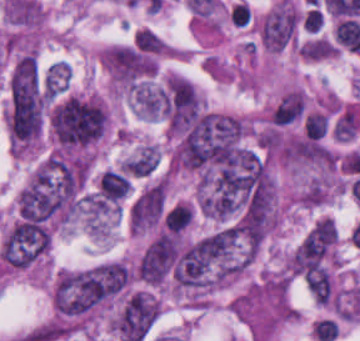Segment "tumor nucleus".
Instances as JSON below:
<instances>
[{"mask_svg": "<svg viewBox=\"0 0 360 341\" xmlns=\"http://www.w3.org/2000/svg\"><path fill=\"white\" fill-rule=\"evenodd\" d=\"M166 203V179H158L134 198L129 212L132 230L139 231L159 224L163 219Z\"/></svg>", "mask_w": 360, "mask_h": 341, "instance_id": "tumor-nucleus-3", "label": "tumor nucleus"}, {"mask_svg": "<svg viewBox=\"0 0 360 341\" xmlns=\"http://www.w3.org/2000/svg\"><path fill=\"white\" fill-rule=\"evenodd\" d=\"M159 159V150L153 144H146L124 160L122 170L131 177L153 173Z\"/></svg>", "mask_w": 360, "mask_h": 341, "instance_id": "tumor-nucleus-4", "label": "tumor nucleus"}, {"mask_svg": "<svg viewBox=\"0 0 360 341\" xmlns=\"http://www.w3.org/2000/svg\"><path fill=\"white\" fill-rule=\"evenodd\" d=\"M49 241L47 219L18 218L0 244L2 259L12 268H26L44 254Z\"/></svg>", "mask_w": 360, "mask_h": 341, "instance_id": "tumor-nucleus-2", "label": "tumor nucleus"}, {"mask_svg": "<svg viewBox=\"0 0 360 341\" xmlns=\"http://www.w3.org/2000/svg\"><path fill=\"white\" fill-rule=\"evenodd\" d=\"M52 123L62 144H87L102 136L106 109L94 100L72 94L52 113Z\"/></svg>", "mask_w": 360, "mask_h": 341, "instance_id": "tumor-nucleus-1", "label": "tumor nucleus"}, {"mask_svg": "<svg viewBox=\"0 0 360 341\" xmlns=\"http://www.w3.org/2000/svg\"><path fill=\"white\" fill-rule=\"evenodd\" d=\"M70 70L64 61H57L48 68L44 78L46 94H62L67 90Z\"/></svg>", "mask_w": 360, "mask_h": 341, "instance_id": "tumor-nucleus-5", "label": "tumor nucleus"}]
</instances>
